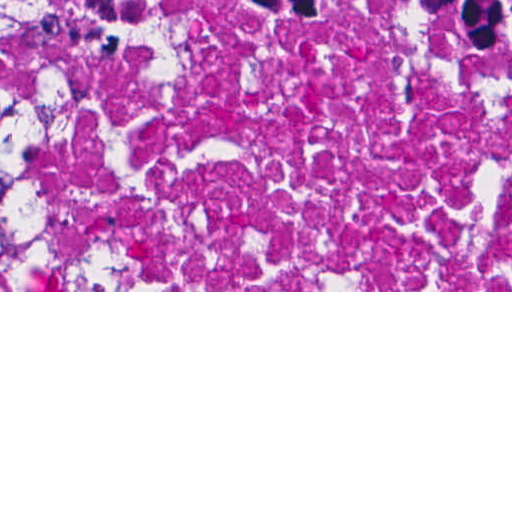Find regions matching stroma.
I'll use <instances>...</instances> for the list:
<instances>
[{"label": "stroma", "instance_id": "stroma-1", "mask_svg": "<svg viewBox=\"0 0 512 512\" xmlns=\"http://www.w3.org/2000/svg\"><path fill=\"white\" fill-rule=\"evenodd\" d=\"M254 12H498L512 0H0V15H219ZM244 14L229 17L240 20ZM0 292H512V290H26L8 258L0 226Z\"/></svg>", "mask_w": 512, "mask_h": 512}]
</instances>
